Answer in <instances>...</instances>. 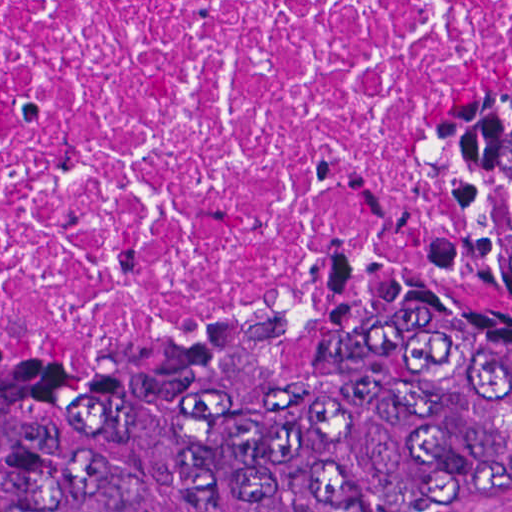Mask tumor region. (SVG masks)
<instances>
[{"mask_svg": "<svg viewBox=\"0 0 512 512\" xmlns=\"http://www.w3.org/2000/svg\"><path fill=\"white\" fill-rule=\"evenodd\" d=\"M512 500V93L401 212L144 365L0 361V512Z\"/></svg>", "mask_w": 512, "mask_h": 512, "instance_id": "obj_1", "label": "tumor region"}]
</instances>
